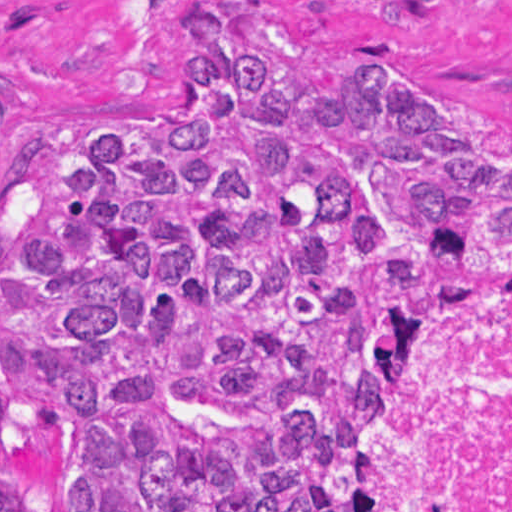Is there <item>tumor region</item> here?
<instances>
[{"label": "tumor region", "mask_w": 512, "mask_h": 512, "mask_svg": "<svg viewBox=\"0 0 512 512\" xmlns=\"http://www.w3.org/2000/svg\"><path fill=\"white\" fill-rule=\"evenodd\" d=\"M174 123L0 134V512H322L360 366L512 285V146L232 0Z\"/></svg>", "instance_id": "obj_1"}]
</instances>
